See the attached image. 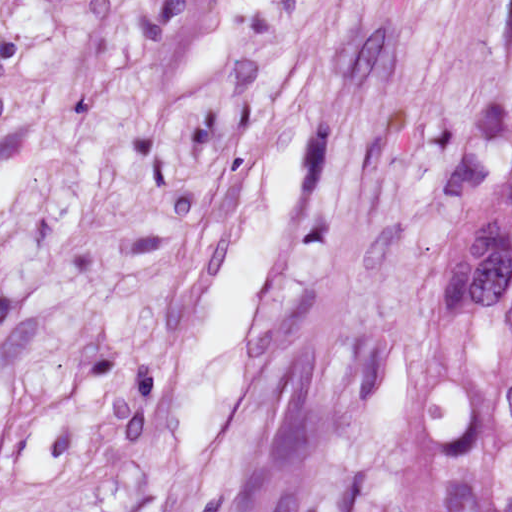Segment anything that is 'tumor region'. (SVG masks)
Returning <instances> with one entry per match:
<instances>
[{"label":"tumor region","mask_w":512,"mask_h":512,"mask_svg":"<svg viewBox=\"0 0 512 512\" xmlns=\"http://www.w3.org/2000/svg\"><path fill=\"white\" fill-rule=\"evenodd\" d=\"M446 153L458 190L433 274L425 491L431 512H512V110L476 106Z\"/></svg>","instance_id":"e687c5a6"}]
</instances>
